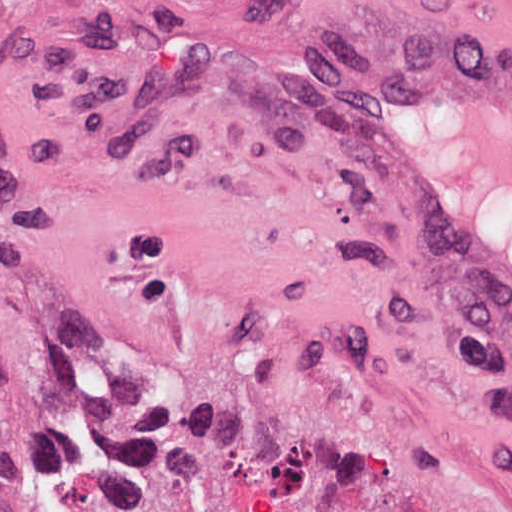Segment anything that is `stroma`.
<instances>
[{"label":"stroma","mask_w":512,"mask_h":512,"mask_svg":"<svg viewBox=\"0 0 512 512\" xmlns=\"http://www.w3.org/2000/svg\"><path fill=\"white\" fill-rule=\"evenodd\" d=\"M300 52L508 57L512 0H0L25 512L78 419L91 512H512V380Z\"/></svg>","instance_id":"stroma-1"}]
</instances>
